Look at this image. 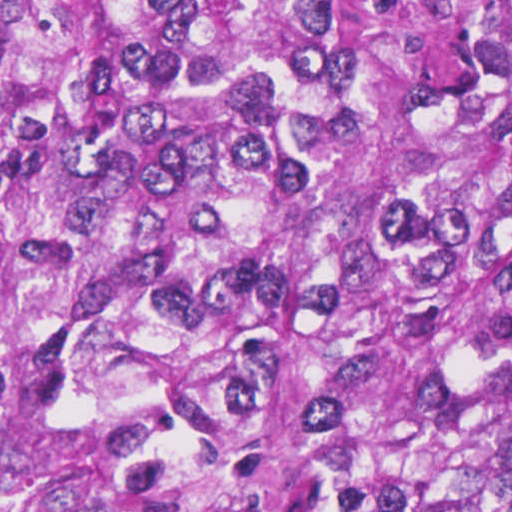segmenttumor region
Returning a JSON list of instances; mask_svg holds the SVG:
<instances>
[{
  "mask_svg": "<svg viewBox=\"0 0 512 512\" xmlns=\"http://www.w3.org/2000/svg\"><path fill=\"white\" fill-rule=\"evenodd\" d=\"M0 512H512V0H0Z\"/></svg>",
  "mask_w": 512,
  "mask_h": 512,
  "instance_id": "tumor-region-1",
  "label": "tumor region"
}]
</instances>
